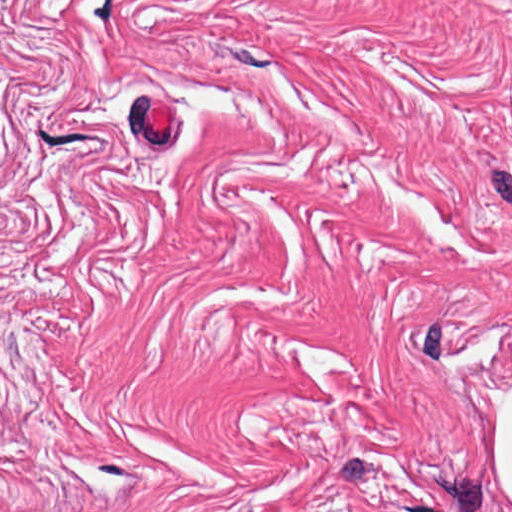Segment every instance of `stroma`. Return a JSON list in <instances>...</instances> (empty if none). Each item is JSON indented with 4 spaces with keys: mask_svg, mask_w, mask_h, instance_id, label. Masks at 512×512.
<instances>
[{
    "mask_svg": "<svg viewBox=\"0 0 512 512\" xmlns=\"http://www.w3.org/2000/svg\"><path fill=\"white\" fill-rule=\"evenodd\" d=\"M512 0H0V512H512Z\"/></svg>",
    "mask_w": 512,
    "mask_h": 512,
    "instance_id": "stroma-1",
    "label": "stroma"
}]
</instances>
